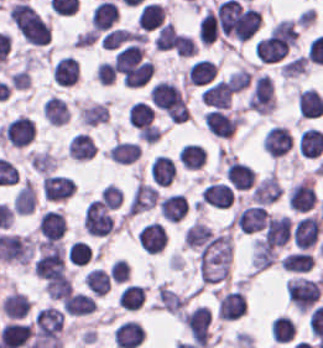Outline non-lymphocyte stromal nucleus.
Listing matches in <instances>:
<instances>
[{
	"label": "non-lymphocyte stromal nucleus",
	"mask_w": 323,
	"mask_h": 348,
	"mask_svg": "<svg viewBox=\"0 0 323 348\" xmlns=\"http://www.w3.org/2000/svg\"><path fill=\"white\" fill-rule=\"evenodd\" d=\"M281 187L279 179L270 172L256 185L252 197L255 202L270 204L279 198Z\"/></svg>",
	"instance_id": "obj_5"
},
{
	"label": "non-lymphocyte stromal nucleus",
	"mask_w": 323,
	"mask_h": 348,
	"mask_svg": "<svg viewBox=\"0 0 323 348\" xmlns=\"http://www.w3.org/2000/svg\"><path fill=\"white\" fill-rule=\"evenodd\" d=\"M213 235V229L201 222L188 225L183 238L188 248H203Z\"/></svg>",
	"instance_id": "obj_7"
},
{
	"label": "non-lymphocyte stromal nucleus",
	"mask_w": 323,
	"mask_h": 348,
	"mask_svg": "<svg viewBox=\"0 0 323 348\" xmlns=\"http://www.w3.org/2000/svg\"><path fill=\"white\" fill-rule=\"evenodd\" d=\"M231 261V233L226 230L211 238L200 250V279L209 284L226 279L230 274Z\"/></svg>",
	"instance_id": "obj_1"
},
{
	"label": "non-lymphocyte stromal nucleus",
	"mask_w": 323,
	"mask_h": 348,
	"mask_svg": "<svg viewBox=\"0 0 323 348\" xmlns=\"http://www.w3.org/2000/svg\"><path fill=\"white\" fill-rule=\"evenodd\" d=\"M236 225L241 233H255L265 229L268 220L265 208L257 204L244 207L236 216Z\"/></svg>",
	"instance_id": "obj_2"
},
{
	"label": "non-lymphocyte stromal nucleus",
	"mask_w": 323,
	"mask_h": 348,
	"mask_svg": "<svg viewBox=\"0 0 323 348\" xmlns=\"http://www.w3.org/2000/svg\"><path fill=\"white\" fill-rule=\"evenodd\" d=\"M158 191L157 187L151 183L137 182L128 206L131 214H138L148 209L157 202Z\"/></svg>",
	"instance_id": "obj_3"
},
{
	"label": "non-lymphocyte stromal nucleus",
	"mask_w": 323,
	"mask_h": 348,
	"mask_svg": "<svg viewBox=\"0 0 323 348\" xmlns=\"http://www.w3.org/2000/svg\"><path fill=\"white\" fill-rule=\"evenodd\" d=\"M275 247L263 240L255 238L251 264L258 270L266 269L275 261Z\"/></svg>",
	"instance_id": "obj_6"
},
{
	"label": "non-lymphocyte stromal nucleus",
	"mask_w": 323,
	"mask_h": 348,
	"mask_svg": "<svg viewBox=\"0 0 323 348\" xmlns=\"http://www.w3.org/2000/svg\"><path fill=\"white\" fill-rule=\"evenodd\" d=\"M291 232V221L283 214L268 219L262 239L275 246H282Z\"/></svg>",
	"instance_id": "obj_4"
}]
</instances>
